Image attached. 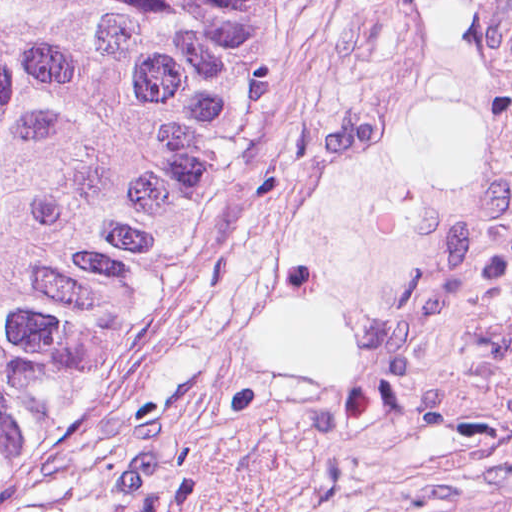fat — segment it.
<instances>
[{"label":"fat","instance_id":"1","mask_svg":"<svg viewBox=\"0 0 512 512\" xmlns=\"http://www.w3.org/2000/svg\"><path fill=\"white\" fill-rule=\"evenodd\" d=\"M423 81L263 297L258 346L340 377L392 363L438 298L500 140L512 0H418Z\"/></svg>","mask_w":512,"mask_h":512}]
</instances>
